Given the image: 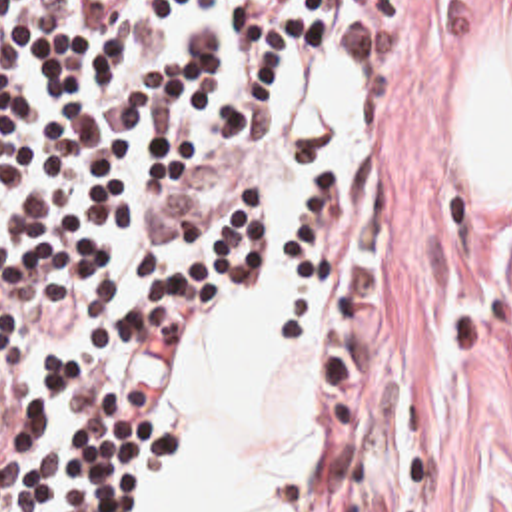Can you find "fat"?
<instances>
[{"label": "fat", "mask_w": 512, "mask_h": 512, "mask_svg": "<svg viewBox=\"0 0 512 512\" xmlns=\"http://www.w3.org/2000/svg\"><path fill=\"white\" fill-rule=\"evenodd\" d=\"M477 193L512 209V37L465 105ZM328 285L244 297L182 371L168 512H304L316 458V331Z\"/></svg>", "instance_id": "obj_1"}]
</instances>
